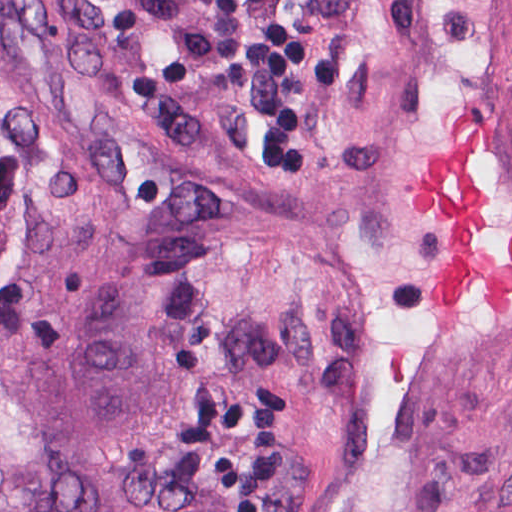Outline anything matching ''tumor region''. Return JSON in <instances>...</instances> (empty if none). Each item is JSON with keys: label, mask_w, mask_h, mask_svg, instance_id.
Listing matches in <instances>:
<instances>
[{"label": "tumor region", "mask_w": 512, "mask_h": 512, "mask_svg": "<svg viewBox=\"0 0 512 512\" xmlns=\"http://www.w3.org/2000/svg\"><path fill=\"white\" fill-rule=\"evenodd\" d=\"M210 226L132 111L0 0V512H237Z\"/></svg>", "instance_id": "tumor-region-1"}]
</instances>
